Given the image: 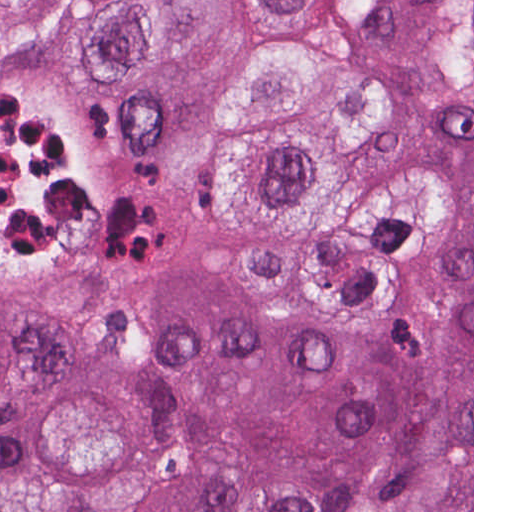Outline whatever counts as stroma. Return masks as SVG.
<instances>
[{
	"mask_svg": "<svg viewBox=\"0 0 512 512\" xmlns=\"http://www.w3.org/2000/svg\"><path fill=\"white\" fill-rule=\"evenodd\" d=\"M144 0H0V274L80 269L127 236L130 195L79 99L85 29ZM474 512V0H472Z\"/></svg>",
	"mask_w": 512,
	"mask_h": 512,
	"instance_id": "1",
	"label": "stroma"
}]
</instances>
